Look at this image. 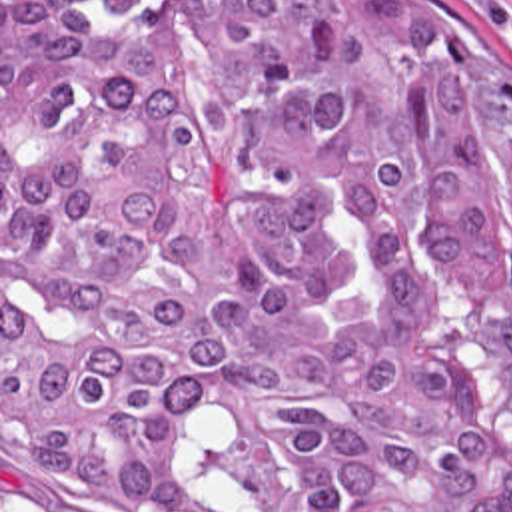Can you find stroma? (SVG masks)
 <instances>
[{
	"label": "stroma",
	"instance_id": "obj_1",
	"mask_svg": "<svg viewBox=\"0 0 512 512\" xmlns=\"http://www.w3.org/2000/svg\"><path fill=\"white\" fill-rule=\"evenodd\" d=\"M92 3V0H84ZM411 21L443 40L479 78H512V0H399ZM512 396V332L465 320ZM108 512L40 502L12 482L8 470V418L2 406V0H0V512Z\"/></svg>",
	"mask_w": 512,
	"mask_h": 512
}]
</instances>
